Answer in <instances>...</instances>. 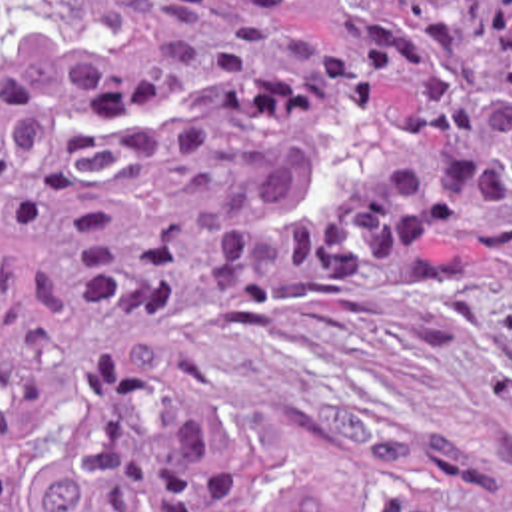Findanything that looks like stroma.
Returning a JSON list of instances; mask_svg holds the SVG:
<instances>
[{"label":"stroma","instance_id":"obj_1","mask_svg":"<svg viewBox=\"0 0 512 512\" xmlns=\"http://www.w3.org/2000/svg\"><path fill=\"white\" fill-rule=\"evenodd\" d=\"M323 26L307 0H279ZM257 460L349 505L377 471L512 499V296L253 292L173 330Z\"/></svg>","mask_w":512,"mask_h":512}]
</instances>
